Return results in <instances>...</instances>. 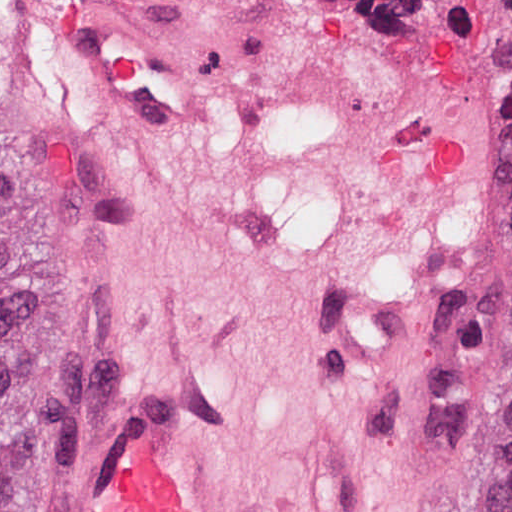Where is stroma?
Segmentation results:
<instances>
[{"instance_id": "stroma-1", "label": "stroma", "mask_w": 512, "mask_h": 512, "mask_svg": "<svg viewBox=\"0 0 512 512\" xmlns=\"http://www.w3.org/2000/svg\"><path fill=\"white\" fill-rule=\"evenodd\" d=\"M478 1L0 0L82 301L29 512H512Z\"/></svg>"}]
</instances>
